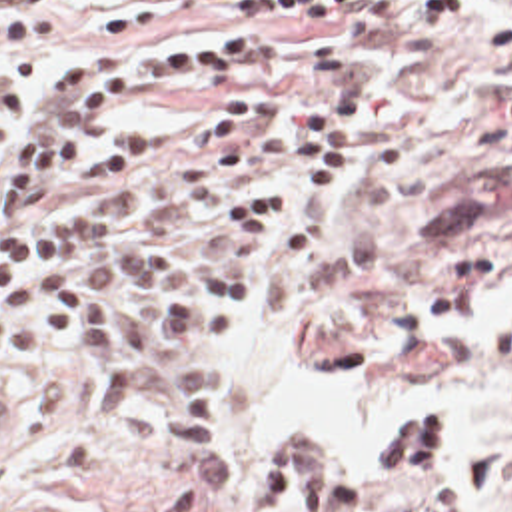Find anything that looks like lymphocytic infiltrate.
<instances>
[{
	"label": "lymphocytic infiltrate",
	"mask_w": 512,
	"mask_h": 512,
	"mask_svg": "<svg viewBox=\"0 0 512 512\" xmlns=\"http://www.w3.org/2000/svg\"><path fill=\"white\" fill-rule=\"evenodd\" d=\"M74 0H8L0 46L44 44ZM473 0H416L444 22ZM402 0H116L100 30L144 32L174 18L252 24L158 38L130 52H76L48 76L0 70V343L12 353L82 337L96 351V403L108 417L136 407L152 351L164 399V447L194 469L206 503L238 489L218 447L222 373L204 347L224 341L230 301L250 291L258 242L288 202L296 162L308 160L288 224V257L330 238L354 154V120L368 76L362 52ZM286 16H312L308 48L278 58ZM491 54L512 60V0H493ZM144 102L216 104L162 168L88 206L34 210L72 184L136 174L144 144L100 136ZM150 337L168 339L140 349ZM463 411L426 395L392 427L378 469H344L326 451H300L288 475H268L264 512H364L372 485L436 481L459 451ZM440 449V467H430Z\"/></svg>",
	"instance_id": "f902f5d3"
}]
</instances>
